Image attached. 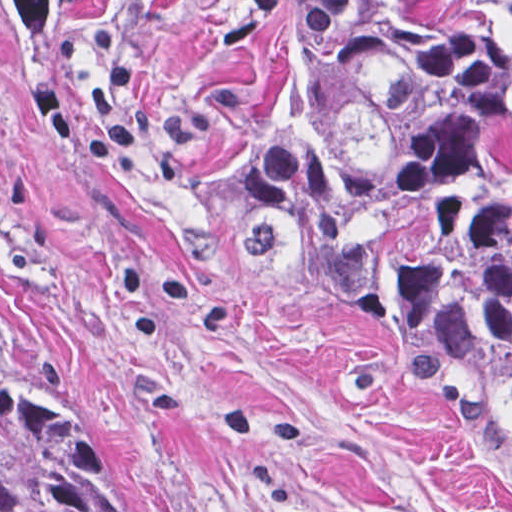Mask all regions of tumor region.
Wrapping results in <instances>:
<instances>
[{"instance_id":"obj_1","label":"tumor region","mask_w":512,"mask_h":512,"mask_svg":"<svg viewBox=\"0 0 512 512\" xmlns=\"http://www.w3.org/2000/svg\"><path fill=\"white\" fill-rule=\"evenodd\" d=\"M20 51L70 0H0ZM309 104L235 193L252 260L512 448V0H331ZM0 512H175L131 418L59 367L0 291Z\"/></svg>"}]
</instances>
